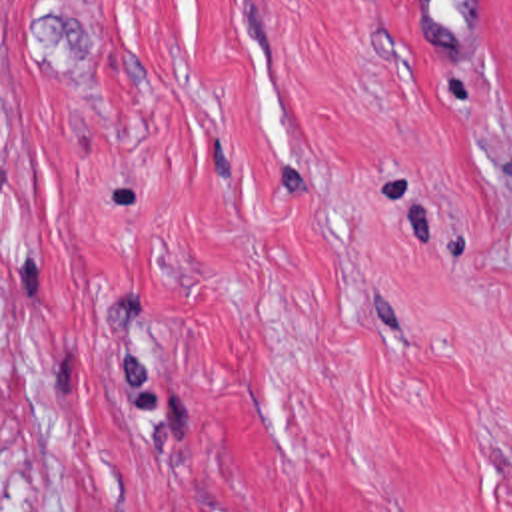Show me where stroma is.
Here are the masks:
<instances>
[{
  "mask_svg": "<svg viewBox=\"0 0 512 512\" xmlns=\"http://www.w3.org/2000/svg\"><path fill=\"white\" fill-rule=\"evenodd\" d=\"M0 512H512V0H0Z\"/></svg>",
  "mask_w": 512,
  "mask_h": 512,
  "instance_id": "obj_1",
  "label": "stroma"
}]
</instances>
